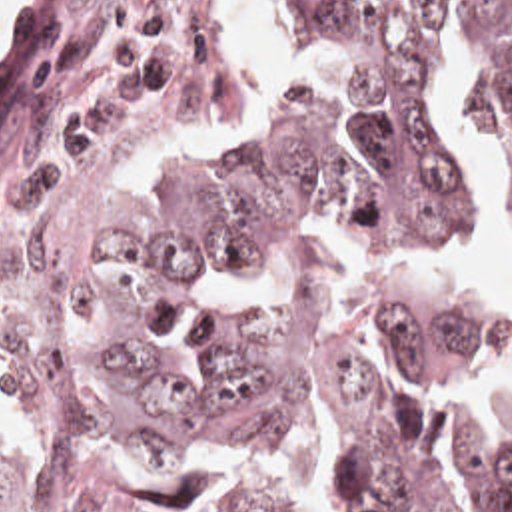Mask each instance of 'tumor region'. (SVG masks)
<instances>
[{
    "instance_id": "e687c5a6",
    "label": "tumor region",
    "mask_w": 512,
    "mask_h": 512,
    "mask_svg": "<svg viewBox=\"0 0 512 512\" xmlns=\"http://www.w3.org/2000/svg\"><path fill=\"white\" fill-rule=\"evenodd\" d=\"M368 70L370 136L340 150L304 98L260 144L134 198L132 158L226 108L234 62L206 0H45L0 74V350L45 440L35 468L0 446V512H270L242 488L204 504L140 488L152 468L288 440L328 402L336 512H512V422L458 406L456 490L428 472L390 374L512 360V310L446 268L394 284L338 330L208 312L202 280L282 242L308 212L390 244L458 236L470 192L434 96L448 0H294ZM474 70L512 164V0H474Z\"/></svg>"
}]
</instances>
